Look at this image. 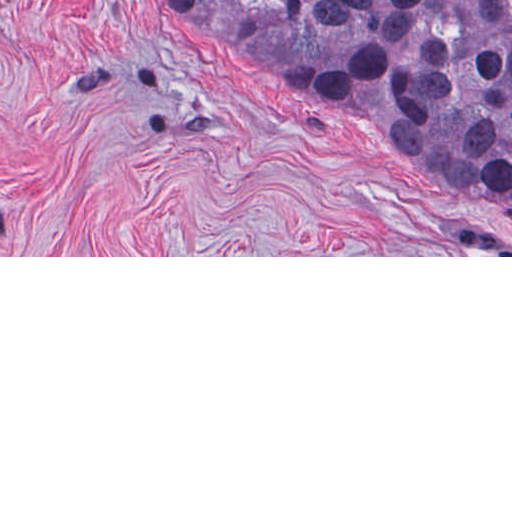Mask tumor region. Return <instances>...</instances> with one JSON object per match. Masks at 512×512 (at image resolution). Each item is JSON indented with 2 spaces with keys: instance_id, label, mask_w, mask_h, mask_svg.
<instances>
[{
  "instance_id": "1",
  "label": "tumor region",
  "mask_w": 512,
  "mask_h": 512,
  "mask_svg": "<svg viewBox=\"0 0 512 512\" xmlns=\"http://www.w3.org/2000/svg\"><path fill=\"white\" fill-rule=\"evenodd\" d=\"M305 108L512 205V0H161Z\"/></svg>"
}]
</instances>
